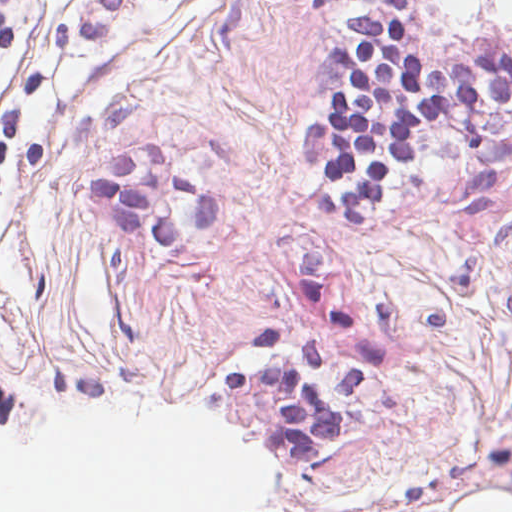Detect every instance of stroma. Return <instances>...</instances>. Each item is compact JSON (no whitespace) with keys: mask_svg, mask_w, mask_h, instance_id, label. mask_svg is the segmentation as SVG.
I'll use <instances>...</instances> for the list:
<instances>
[{"mask_svg":"<svg viewBox=\"0 0 512 512\" xmlns=\"http://www.w3.org/2000/svg\"><path fill=\"white\" fill-rule=\"evenodd\" d=\"M408 0L426 61L512 50ZM386 0H0V340L194 391L321 389L327 447L512 506V106L434 133L376 220H326L299 149L335 47Z\"/></svg>","mask_w":512,"mask_h":512,"instance_id":"obj_1","label":"stroma"}]
</instances>
